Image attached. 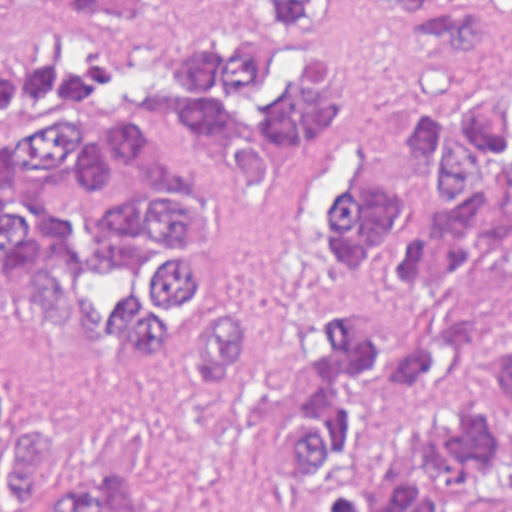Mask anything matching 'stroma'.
Returning a JSON list of instances; mask_svg holds the SVG:
<instances>
[{"instance_id":"1","label":"stroma","mask_w":512,"mask_h":512,"mask_svg":"<svg viewBox=\"0 0 512 512\" xmlns=\"http://www.w3.org/2000/svg\"><path fill=\"white\" fill-rule=\"evenodd\" d=\"M1 1H356L361 31L338 68L342 137L315 167L280 188L232 176L160 123L157 141L204 199L192 282L252 300L297 263L305 198L329 163H381L397 146L400 108L421 86L512 61V0H0V512H1ZM365 297L386 333L443 332L459 392L443 404L380 407L360 420L354 460L381 482L407 447L450 420L479 390L497 352L512 346V269L458 263L423 291L387 288L354 263L313 259L277 286L259 342L225 397L187 399L171 348L152 356H98L43 309L23 302L12 396L43 422L58 481L94 458H117L150 486L164 512H313L270 463V438L317 342L325 300Z\"/></svg>"}]
</instances>
